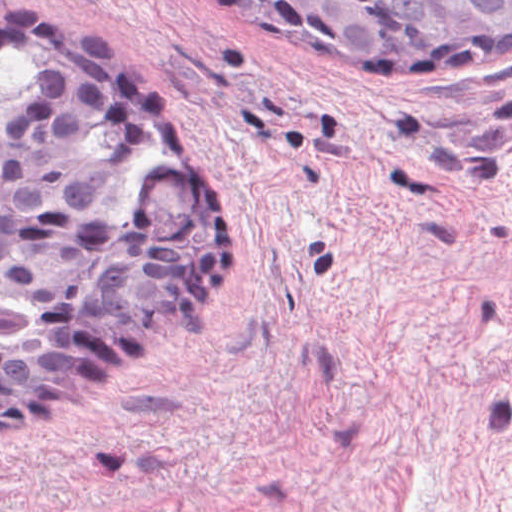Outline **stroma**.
<instances>
[{"instance_id":"1","label":"stroma","mask_w":512,"mask_h":512,"mask_svg":"<svg viewBox=\"0 0 512 512\" xmlns=\"http://www.w3.org/2000/svg\"><path fill=\"white\" fill-rule=\"evenodd\" d=\"M231 208L216 288L21 430L0 512H512V67L308 44L241 0H0Z\"/></svg>"}]
</instances>
